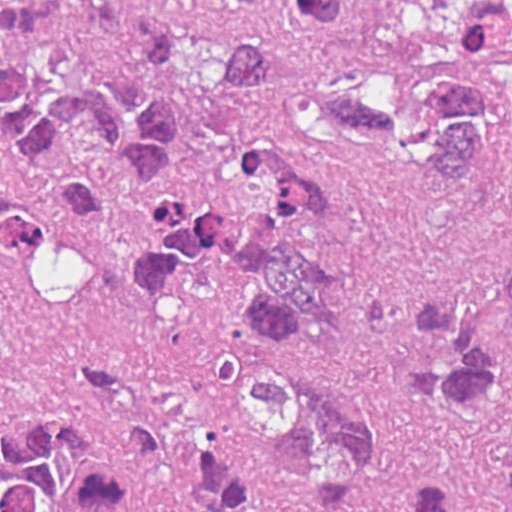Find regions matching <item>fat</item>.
Masks as SVG:
<instances>
[{
  "label": "fat",
  "mask_w": 512,
  "mask_h": 512,
  "mask_svg": "<svg viewBox=\"0 0 512 512\" xmlns=\"http://www.w3.org/2000/svg\"><path fill=\"white\" fill-rule=\"evenodd\" d=\"M46 240L29 272L41 298L83 312L95 300V269L84 249L65 239Z\"/></svg>",
  "instance_id": "fat-1"
}]
</instances>
